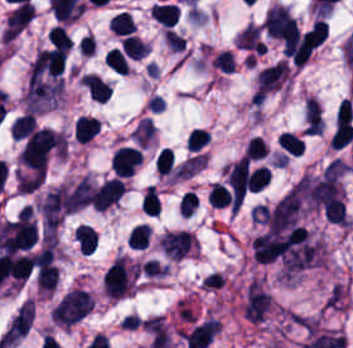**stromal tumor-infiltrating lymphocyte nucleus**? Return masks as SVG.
<instances>
[{"instance_id":"stromal-tumor-infiltrating-lymphocyte-nucleus-1","label":"stromal tumor-infiltrating lymphocyte nucleus","mask_w":353,"mask_h":348,"mask_svg":"<svg viewBox=\"0 0 353 348\" xmlns=\"http://www.w3.org/2000/svg\"><path fill=\"white\" fill-rule=\"evenodd\" d=\"M249 166L245 155L226 165V182L232 200H242L247 188Z\"/></svg>"},{"instance_id":"stromal-tumor-infiltrating-lymphocyte-nucleus-2","label":"stromal tumor-infiltrating lymphocyte nucleus","mask_w":353,"mask_h":348,"mask_svg":"<svg viewBox=\"0 0 353 348\" xmlns=\"http://www.w3.org/2000/svg\"><path fill=\"white\" fill-rule=\"evenodd\" d=\"M141 159L136 148L119 146L114 150L110 159V168L119 177L131 175Z\"/></svg>"},{"instance_id":"stromal-tumor-infiltrating-lymphocyte-nucleus-3","label":"stromal tumor-infiltrating lymphocyte nucleus","mask_w":353,"mask_h":348,"mask_svg":"<svg viewBox=\"0 0 353 348\" xmlns=\"http://www.w3.org/2000/svg\"><path fill=\"white\" fill-rule=\"evenodd\" d=\"M150 14L162 26L170 27L178 17L179 11L174 3H154Z\"/></svg>"},{"instance_id":"stromal-tumor-infiltrating-lymphocyte-nucleus-4","label":"stromal tumor-infiltrating lymphocyte nucleus","mask_w":353,"mask_h":348,"mask_svg":"<svg viewBox=\"0 0 353 348\" xmlns=\"http://www.w3.org/2000/svg\"><path fill=\"white\" fill-rule=\"evenodd\" d=\"M98 132V119L92 116L80 115L77 118V142H87Z\"/></svg>"},{"instance_id":"stromal-tumor-infiltrating-lymphocyte-nucleus-5","label":"stromal tumor-infiltrating lymphocyte nucleus","mask_w":353,"mask_h":348,"mask_svg":"<svg viewBox=\"0 0 353 348\" xmlns=\"http://www.w3.org/2000/svg\"><path fill=\"white\" fill-rule=\"evenodd\" d=\"M134 21L130 13L126 11H119L111 16L107 28L115 35H128L133 26Z\"/></svg>"},{"instance_id":"stromal-tumor-infiltrating-lymphocyte-nucleus-6","label":"stromal tumor-infiltrating lymphocyte nucleus","mask_w":353,"mask_h":348,"mask_svg":"<svg viewBox=\"0 0 353 348\" xmlns=\"http://www.w3.org/2000/svg\"><path fill=\"white\" fill-rule=\"evenodd\" d=\"M147 45L136 37L124 35L121 40V52L131 60H139L145 53Z\"/></svg>"},{"instance_id":"stromal-tumor-infiltrating-lymphocyte-nucleus-7","label":"stromal tumor-infiltrating lymphocyte nucleus","mask_w":353,"mask_h":348,"mask_svg":"<svg viewBox=\"0 0 353 348\" xmlns=\"http://www.w3.org/2000/svg\"><path fill=\"white\" fill-rule=\"evenodd\" d=\"M276 142L283 151L295 154L297 156L303 152V140L294 133L280 132L276 136Z\"/></svg>"},{"instance_id":"stromal-tumor-infiltrating-lymphocyte-nucleus-8","label":"stromal tumor-infiltrating lymphocyte nucleus","mask_w":353,"mask_h":348,"mask_svg":"<svg viewBox=\"0 0 353 348\" xmlns=\"http://www.w3.org/2000/svg\"><path fill=\"white\" fill-rule=\"evenodd\" d=\"M270 170L265 166H257L246 175V189L251 191L261 190L268 182Z\"/></svg>"},{"instance_id":"stromal-tumor-infiltrating-lymphocyte-nucleus-9","label":"stromal tumor-infiltrating lymphocyte nucleus","mask_w":353,"mask_h":348,"mask_svg":"<svg viewBox=\"0 0 353 348\" xmlns=\"http://www.w3.org/2000/svg\"><path fill=\"white\" fill-rule=\"evenodd\" d=\"M160 206L159 196L154 188V186H147L144 189L140 208L141 213L148 216H157Z\"/></svg>"},{"instance_id":"stromal-tumor-infiltrating-lymphocyte-nucleus-10","label":"stromal tumor-infiltrating lymphocyte nucleus","mask_w":353,"mask_h":348,"mask_svg":"<svg viewBox=\"0 0 353 348\" xmlns=\"http://www.w3.org/2000/svg\"><path fill=\"white\" fill-rule=\"evenodd\" d=\"M103 61L110 70L116 74H124L126 72V59L118 47H111L105 52Z\"/></svg>"},{"instance_id":"stromal-tumor-infiltrating-lymphocyte-nucleus-11","label":"stromal tumor-infiltrating lymphocyte nucleus","mask_w":353,"mask_h":348,"mask_svg":"<svg viewBox=\"0 0 353 348\" xmlns=\"http://www.w3.org/2000/svg\"><path fill=\"white\" fill-rule=\"evenodd\" d=\"M48 42L57 49L68 51L72 45V39L60 26H53L47 34Z\"/></svg>"},{"instance_id":"stromal-tumor-infiltrating-lymphocyte-nucleus-12","label":"stromal tumor-infiltrating lymphocyte nucleus","mask_w":353,"mask_h":348,"mask_svg":"<svg viewBox=\"0 0 353 348\" xmlns=\"http://www.w3.org/2000/svg\"><path fill=\"white\" fill-rule=\"evenodd\" d=\"M231 193L229 190L219 183H212L210 190L207 194V204L223 207L228 205Z\"/></svg>"},{"instance_id":"stromal-tumor-infiltrating-lymphocyte-nucleus-13","label":"stromal tumor-infiltrating lymphocyte nucleus","mask_w":353,"mask_h":348,"mask_svg":"<svg viewBox=\"0 0 353 348\" xmlns=\"http://www.w3.org/2000/svg\"><path fill=\"white\" fill-rule=\"evenodd\" d=\"M174 162L173 151L170 148H162L154 158L156 172L169 174Z\"/></svg>"},{"instance_id":"stromal-tumor-infiltrating-lymphocyte-nucleus-14","label":"stromal tumor-infiltrating lymphocyte nucleus","mask_w":353,"mask_h":348,"mask_svg":"<svg viewBox=\"0 0 353 348\" xmlns=\"http://www.w3.org/2000/svg\"><path fill=\"white\" fill-rule=\"evenodd\" d=\"M209 142L207 132L200 128H193L187 136L186 148L189 151H198Z\"/></svg>"},{"instance_id":"stromal-tumor-infiltrating-lymphocyte-nucleus-15","label":"stromal tumor-infiltrating lymphocyte nucleus","mask_w":353,"mask_h":348,"mask_svg":"<svg viewBox=\"0 0 353 348\" xmlns=\"http://www.w3.org/2000/svg\"><path fill=\"white\" fill-rule=\"evenodd\" d=\"M267 153V147L260 136H252L247 147L246 156L253 160L264 158Z\"/></svg>"}]
</instances>
